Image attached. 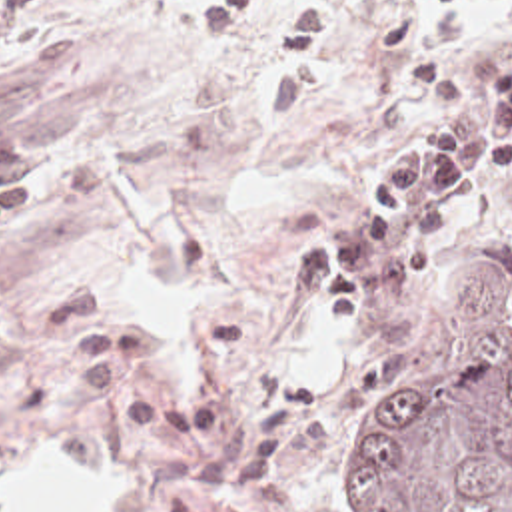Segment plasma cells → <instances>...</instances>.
I'll return each instance as SVG.
<instances>
[{
	"label": "plasma cells",
	"mask_w": 512,
	"mask_h": 512,
	"mask_svg": "<svg viewBox=\"0 0 512 512\" xmlns=\"http://www.w3.org/2000/svg\"><path fill=\"white\" fill-rule=\"evenodd\" d=\"M256 0L198 11L181 21L208 43H228ZM47 19V0H0V67L27 55ZM434 111L428 125L392 146L348 210L298 258L294 280L324 284L332 312H358L366 294L392 300L416 288L444 256L460 216L512 170V27L478 69L462 73L440 55L414 61ZM45 192V160L19 135H0V242Z\"/></svg>",
	"instance_id": "9512152a"
}]
</instances>
